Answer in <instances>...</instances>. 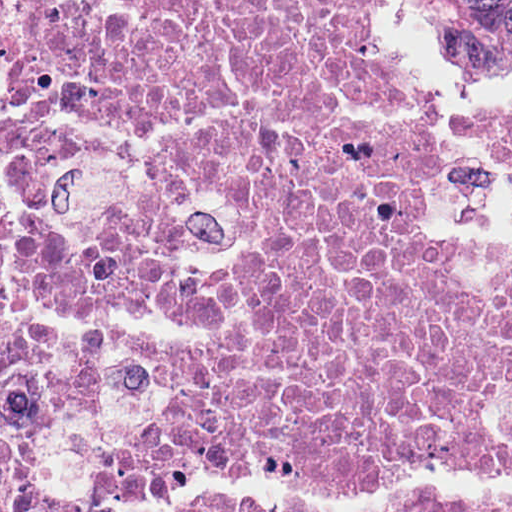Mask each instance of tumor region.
Listing matches in <instances>:
<instances>
[{"label":"tumor region","instance_id":"tumor-region-1","mask_svg":"<svg viewBox=\"0 0 512 512\" xmlns=\"http://www.w3.org/2000/svg\"><path fill=\"white\" fill-rule=\"evenodd\" d=\"M454 65L489 73L512 65V0H424Z\"/></svg>","mask_w":512,"mask_h":512}]
</instances>
